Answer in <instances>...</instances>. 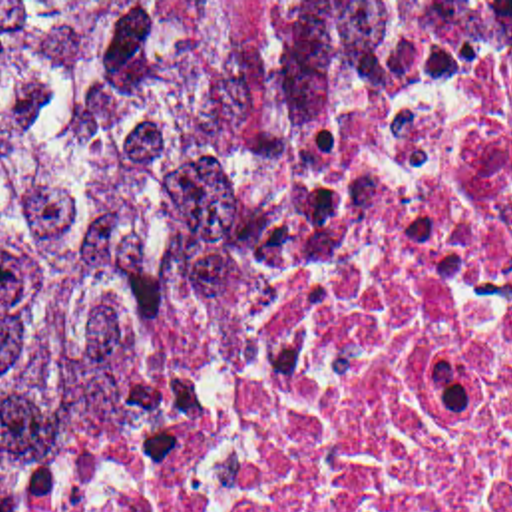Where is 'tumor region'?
<instances>
[{
  "mask_svg": "<svg viewBox=\"0 0 512 512\" xmlns=\"http://www.w3.org/2000/svg\"><path fill=\"white\" fill-rule=\"evenodd\" d=\"M512 2H0V486L372 110Z\"/></svg>",
  "mask_w": 512,
  "mask_h": 512,
  "instance_id": "tumor-region-1",
  "label": "tumor region"
}]
</instances>
